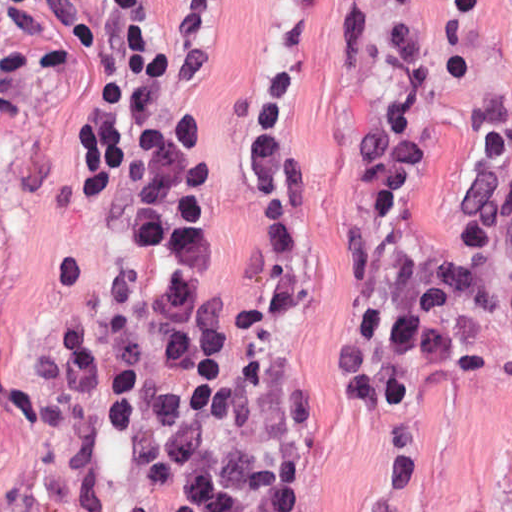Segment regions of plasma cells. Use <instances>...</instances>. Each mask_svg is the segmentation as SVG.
<instances>
[{
  "instance_id": "1",
  "label": "plasma cells",
  "mask_w": 512,
  "mask_h": 512,
  "mask_svg": "<svg viewBox=\"0 0 512 512\" xmlns=\"http://www.w3.org/2000/svg\"><path fill=\"white\" fill-rule=\"evenodd\" d=\"M489 0H444L466 29ZM419 0H351L337 23L335 68L354 70L380 34L375 92L351 133L357 217L341 242L346 270L334 297L330 358L351 399L377 417V479L395 499L412 467L415 417L442 376L495 369L484 329L495 305L490 266L509 268L512 291V108L493 90L479 101L481 142L460 206L455 250L432 268L416 238L414 199L430 162L431 65L416 43ZM289 67H265L251 90L247 165L270 228L269 267L227 314L241 330L297 297V245L305 222L304 174L287 151ZM512 388V338L504 352Z\"/></svg>"
}]
</instances>
